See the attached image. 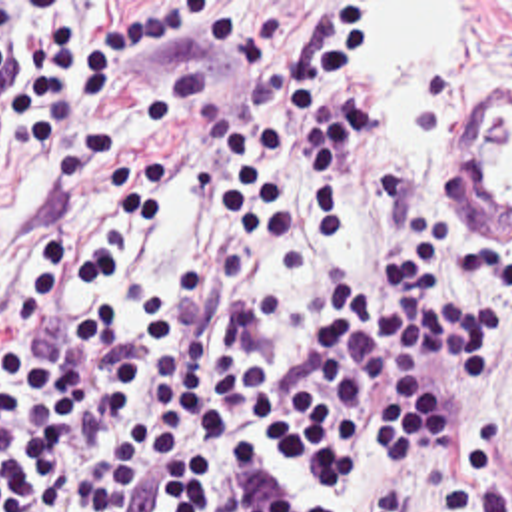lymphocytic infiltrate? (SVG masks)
<instances>
[{"mask_svg":"<svg viewBox=\"0 0 512 512\" xmlns=\"http://www.w3.org/2000/svg\"><path fill=\"white\" fill-rule=\"evenodd\" d=\"M353 14L0 2V512H512L502 415L464 433L427 365L498 373L494 301L456 286L486 240L458 190L413 216L391 284H279Z\"/></svg>","mask_w":512,"mask_h":512,"instance_id":"1","label":"lymphocytic infiltrate"}]
</instances>
